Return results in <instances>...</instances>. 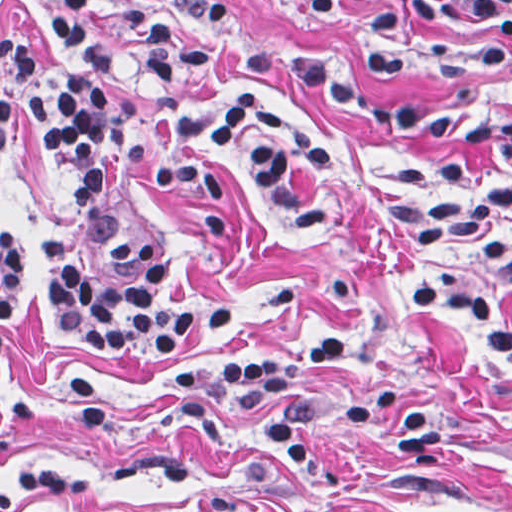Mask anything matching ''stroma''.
<instances>
[{"mask_svg": "<svg viewBox=\"0 0 512 512\" xmlns=\"http://www.w3.org/2000/svg\"><path fill=\"white\" fill-rule=\"evenodd\" d=\"M123 0H104L89 25L120 67L110 85L132 131L154 147L148 165L110 166L101 199L67 235L87 286L112 277L106 238L145 235L161 249L168 283L157 306L185 313L220 305L228 330L203 329L174 353H95L71 347L44 287L39 244L66 203L34 136L16 115L0 144V223L14 233L19 300L3 326L0 372V481L42 466H65L79 492L23 501L12 512H306L308 492L284 472L259 428L267 412L222 404L230 442H206L180 421L204 391L169 394L162 385L196 361H245L261 352L341 333L348 358L300 371L318 395L313 434L326 457L345 452L350 487L342 512H512V366L456 344L412 314L408 280L450 274L512 304V294L470 263L410 244L390 217L379 183L401 154L463 167L452 155L347 115L272 70H212V94L261 88L332 137L342 156L320 219L279 225L258 188L228 169L230 228L214 245L197 238L182 211L156 194L148 174L173 151L161 108L142 87L140 46L116 21ZM158 4L162 0H138ZM375 0H238L236 24L260 39L310 55L354 48ZM49 0H0V30L44 48L34 87L56 90L58 47ZM369 103H407L468 119L512 122V50L481 77L445 74L415 52L384 78L355 83ZM33 90V91H34ZM373 386H410L429 398L441 423L433 465L401 460L384 413L351 421L347 400Z\"/></svg>", "mask_w": 512, "mask_h": 512, "instance_id": "stroma-1", "label": "stroma"}]
</instances>
